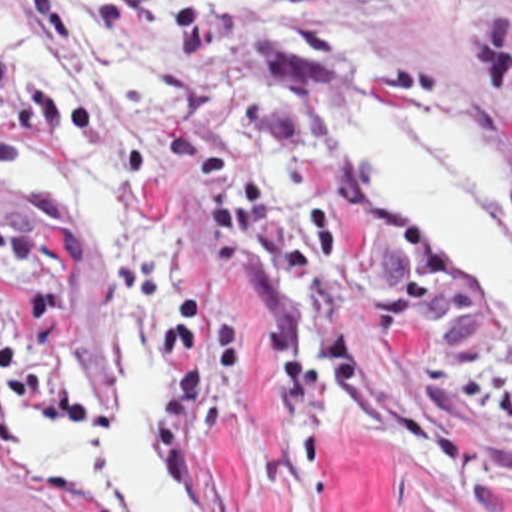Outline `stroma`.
I'll return each mask as SVG.
<instances>
[{
    "label": "stroma",
    "mask_w": 512,
    "mask_h": 512,
    "mask_svg": "<svg viewBox=\"0 0 512 512\" xmlns=\"http://www.w3.org/2000/svg\"><path fill=\"white\" fill-rule=\"evenodd\" d=\"M0 61L167 147L151 175L85 157L0 173V206L39 175L79 193L101 256L83 362L119 410L61 444L15 406L0 494L19 502L1 512H79L37 470L121 430L125 330L175 356L155 458L185 512H512V324L461 302L311 99L315 77H341L483 141L512 268V0L211 1L171 99L39 89Z\"/></svg>",
    "instance_id": "obj_1"
}]
</instances>
